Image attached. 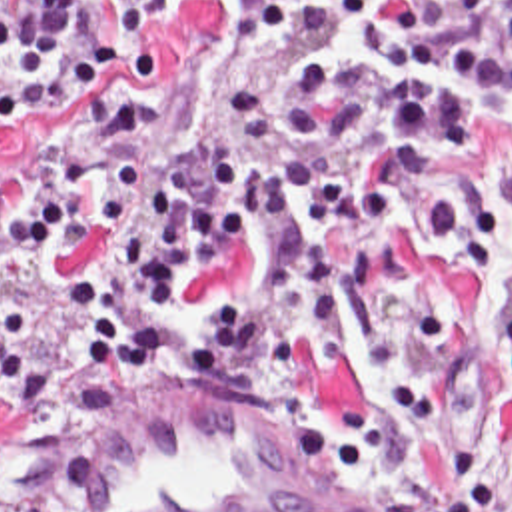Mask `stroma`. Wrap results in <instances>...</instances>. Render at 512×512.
I'll return each mask as SVG.
<instances>
[{
  "instance_id": "stroma-1",
  "label": "stroma",
  "mask_w": 512,
  "mask_h": 512,
  "mask_svg": "<svg viewBox=\"0 0 512 512\" xmlns=\"http://www.w3.org/2000/svg\"><path fill=\"white\" fill-rule=\"evenodd\" d=\"M222 24L238 68H282V54L258 34L256 0H242L236 16L220 0H186L162 6L156 48L158 68L140 74L122 58V12L102 6L98 34L112 42L106 72L86 84L76 100L44 122H0V168L18 184L46 180L108 96L140 102L150 118V152L178 154L198 136L212 110V36ZM512 164V138L494 128L480 132L466 150L442 152L416 146L386 158L368 188L382 196L406 168H496ZM0 298L16 300L26 346L52 352L60 326V294L54 282H34L28 272L0 260ZM446 314L458 320L456 342L436 358L438 374L484 376L490 366L498 320L512 314V250L472 274H448L430 246L418 272L380 276L376 286L348 308L350 324L326 362L294 356V388L280 396H240L218 382L182 372L176 358L150 382L100 384L82 356H66L38 390L0 382V512H44L54 473L82 440L140 412L182 396L260 408L294 426L314 406L370 394L392 384V356L402 332L420 318ZM468 462H490L512 475V410L492 398L404 442L392 454L360 469L390 491L434 471ZM398 507V499H396Z\"/></svg>"
}]
</instances>
